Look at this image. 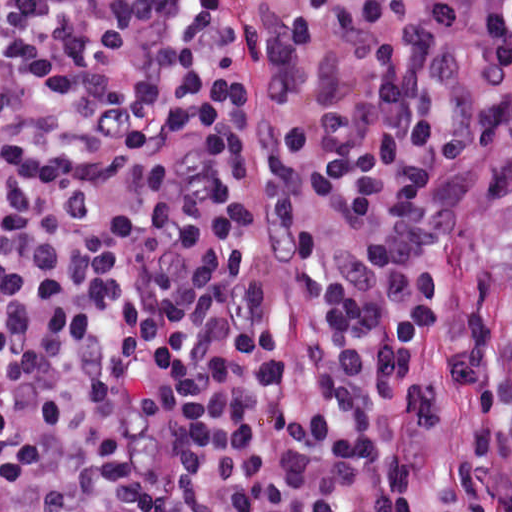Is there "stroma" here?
Wrapping results in <instances>:
<instances>
[{
	"label": "stroma",
	"instance_id": "1",
	"mask_svg": "<svg viewBox=\"0 0 512 512\" xmlns=\"http://www.w3.org/2000/svg\"><path fill=\"white\" fill-rule=\"evenodd\" d=\"M512 170V147L493 149L464 168L431 181L425 197L430 234L444 259L439 313L423 339L410 381L429 387L434 418L391 421L389 432L416 473L409 512H469L455 477L459 450L478 429V391L451 365L463 325L464 287L494 183ZM488 348L493 384L512 419V218L505 223L488 300Z\"/></svg>",
	"mask_w": 512,
	"mask_h": 512
}]
</instances>
